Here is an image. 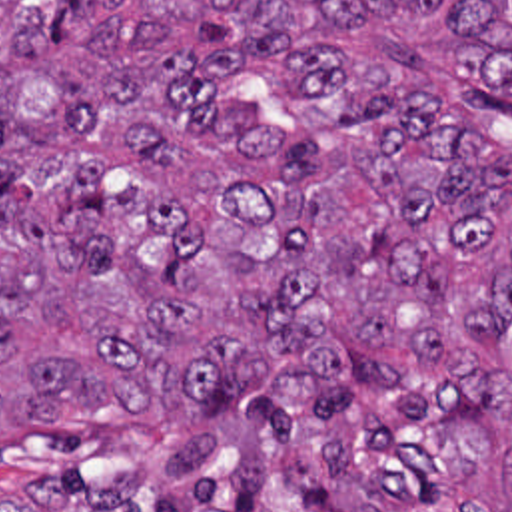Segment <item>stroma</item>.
<instances>
[{
    "label": "stroma",
    "mask_w": 512,
    "mask_h": 512,
    "mask_svg": "<svg viewBox=\"0 0 512 512\" xmlns=\"http://www.w3.org/2000/svg\"><path fill=\"white\" fill-rule=\"evenodd\" d=\"M510 123H512V117H510ZM496 149H498V147H496ZM498 155H500V159H502L504 171H506L508 181H510V185H512V155H508V153H506V151H502V149H498Z\"/></svg>",
    "instance_id": "1"
}]
</instances>
